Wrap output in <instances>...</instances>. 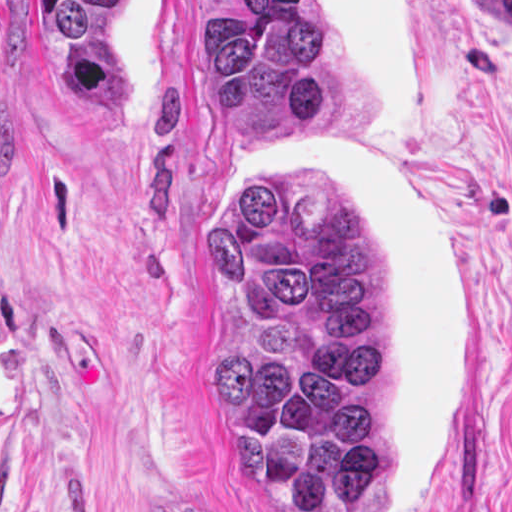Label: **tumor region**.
I'll list each match as a JSON object with an SVG mask.
<instances>
[{"label": "tumor region", "instance_id": "obj_1", "mask_svg": "<svg viewBox=\"0 0 512 512\" xmlns=\"http://www.w3.org/2000/svg\"><path fill=\"white\" fill-rule=\"evenodd\" d=\"M198 62L241 137L333 141L360 113L318 1H231ZM210 387L235 469L282 512H397L390 302L336 170L238 160L212 210Z\"/></svg>", "mask_w": 512, "mask_h": 512}]
</instances>
